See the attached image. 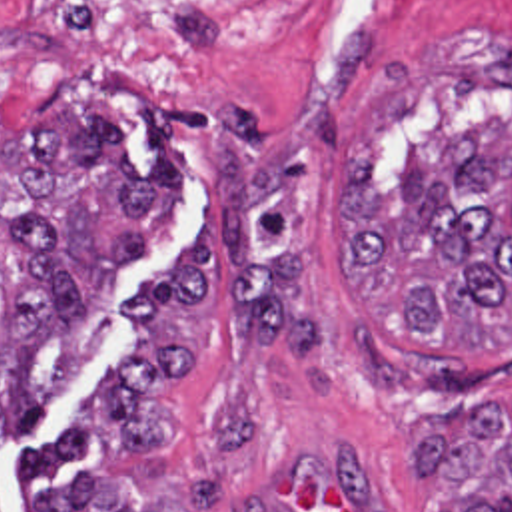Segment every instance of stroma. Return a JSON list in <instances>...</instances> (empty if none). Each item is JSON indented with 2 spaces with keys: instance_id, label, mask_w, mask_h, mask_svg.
I'll return each mask as SVG.
<instances>
[{
  "instance_id": "obj_1",
  "label": "stroma",
  "mask_w": 512,
  "mask_h": 512,
  "mask_svg": "<svg viewBox=\"0 0 512 512\" xmlns=\"http://www.w3.org/2000/svg\"><path fill=\"white\" fill-rule=\"evenodd\" d=\"M64 95L114 117L132 165L152 127L184 209L120 269L114 325L0 444L4 512L94 468L178 512H428L426 428L512 401V339L400 335L344 281V173L364 139L396 185L404 145L512 123V0H276L238 67L188 95L94 85L0 33V139Z\"/></svg>"
}]
</instances>
